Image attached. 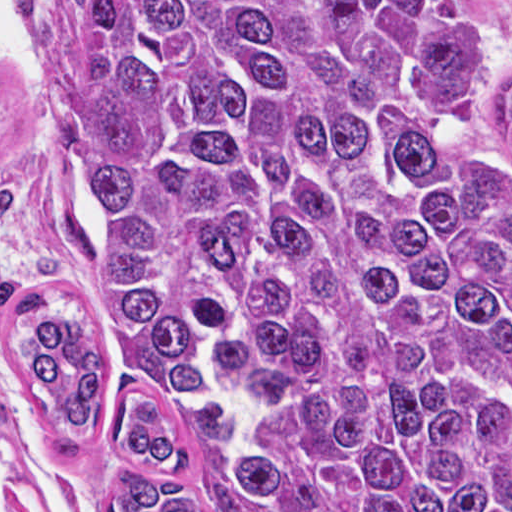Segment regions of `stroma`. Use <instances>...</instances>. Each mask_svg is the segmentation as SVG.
I'll return each mask as SVG.
<instances>
[{"label": "stroma", "mask_w": 512, "mask_h": 512, "mask_svg": "<svg viewBox=\"0 0 512 512\" xmlns=\"http://www.w3.org/2000/svg\"><path fill=\"white\" fill-rule=\"evenodd\" d=\"M459 1L478 26L471 86L512 162L504 125L512 93V0ZM29 52L41 71L34 81L0 55V512H115L114 489L136 475L111 438L97 433L57 455L16 400V342L65 309H93L86 261L38 224L46 212L61 210L84 230L93 210L79 163L53 130L44 73ZM161 395L192 444L180 488L210 512H247L225 470L224 395L215 386H195L176 400Z\"/></svg>", "instance_id": "obj_1"}]
</instances>
